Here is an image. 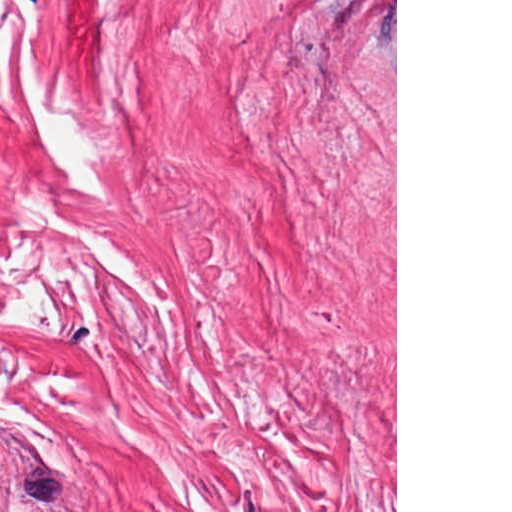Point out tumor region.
I'll use <instances>...</instances> for the list:
<instances>
[{
    "instance_id": "e687c5a6",
    "label": "tumor region",
    "mask_w": 512,
    "mask_h": 512,
    "mask_svg": "<svg viewBox=\"0 0 512 512\" xmlns=\"http://www.w3.org/2000/svg\"><path fill=\"white\" fill-rule=\"evenodd\" d=\"M0 512L25 511L0 487Z\"/></svg>"
}]
</instances>
